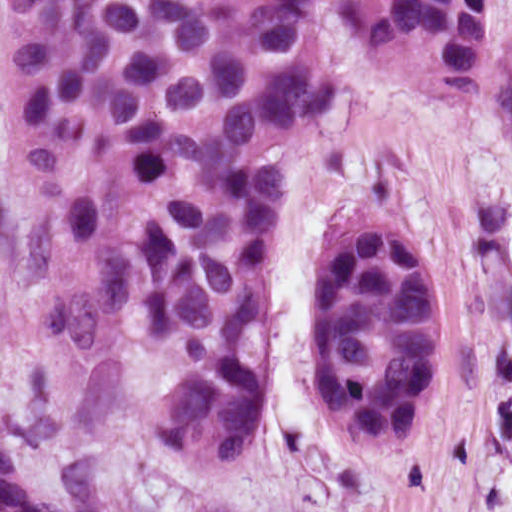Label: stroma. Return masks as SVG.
<instances>
[{
    "label": "stroma",
    "instance_id": "stroma-1",
    "mask_svg": "<svg viewBox=\"0 0 512 512\" xmlns=\"http://www.w3.org/2000/svg\"><path fill=\"white\" fill-rule=\"evenodd\" d=\"M313 46L339 97L290 150L269 220L267 379L235 468L157 449L76 361L25 262L0 26V438L53 502L116 512H512V0H480L476 99L440 101L369 64L324 8ZM429 238L443 361L415 447L362 455L309 385V294L363 213Z\"/></svg>",
    "mask_w": 512,
    "mask_h": 512
}]
</instances>
